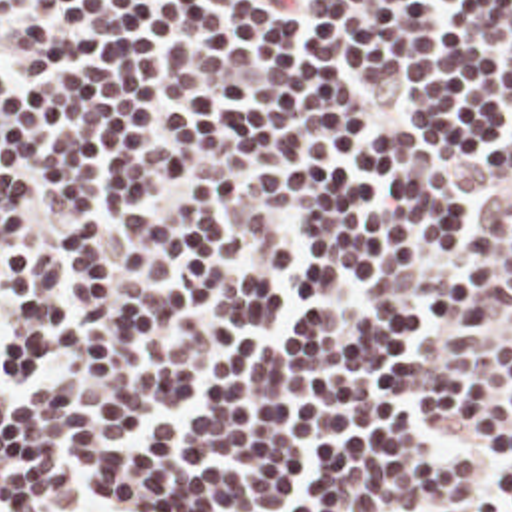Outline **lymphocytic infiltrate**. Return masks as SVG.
<instances>
[{
  "mask_svg": "<svg viewBox=\"0 0 512 512\" xmlns=\"http://www.w3.org/2000/svg\"><path fill=\"white\" fill-rule=\"evenodd\" d=\"M0 512H512V0H0Z\"/></svg>",
  "mask_w": 512,
  "mask_h": 512,
  "instance_id": "lymphocytic-infiltrate-1",
  "label": "lymphocytic infiltrate"
}]
</instances>
